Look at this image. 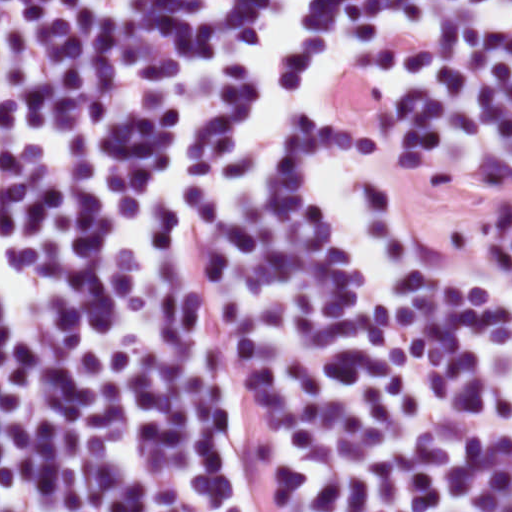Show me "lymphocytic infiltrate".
Returning <instances> with one entry per match:
<instances>
[{
    "label": "lymphocytic infiltrate",
    "mask_w": 512,
    "mask_h": 512,
    "mask_svg": "<svg viewBox=\"0 0 512 512\" xmlns=\"http://www.w3.org/2000/svg\"><path fill=\"white\" fill-rule=\"evenodd\" d=\"M0 512H512V0H0Z\"/></svg>",
    "instance_id": "obj_1"
}]
</instances>
